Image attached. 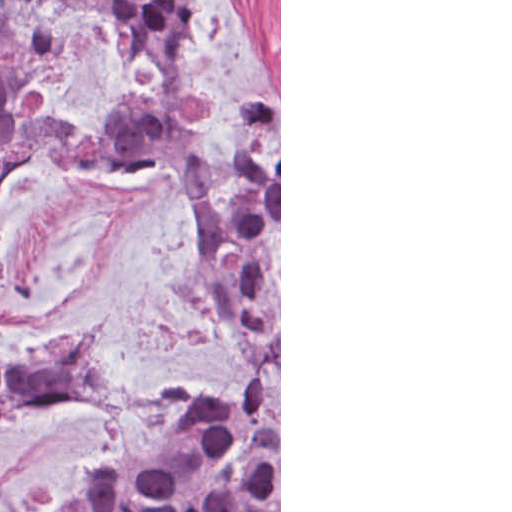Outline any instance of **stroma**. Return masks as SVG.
<instances>
[{"label":"stroma","instance_id":"35a3bbf8","mask_svg":"<svg viewBox=\"0 0 512 512\" xmlns=\"http://www.w3.org/2000/svg\"><path fill=\"white\" fill-rule=\"evenodd\" d=\"M146 0H143L141 18ZM41 49L44 113L80 133L123 100L161 101L157 67L127 60L103 17L40 11L9 28ZM182 82L204 119L187 129L212 174H226L246 122L279 101V512H281V0H196L179 36ZM95 329L115 399L30 413L10 427L0 512H63L90 466L165 451V414L190 391L238 384L242 337L230 303L196 273V186L176 165L130 159L83 169L31 151L0 193V364Z\"/></svg>","mask_w":512,"mask_h":512}]
</instances>
